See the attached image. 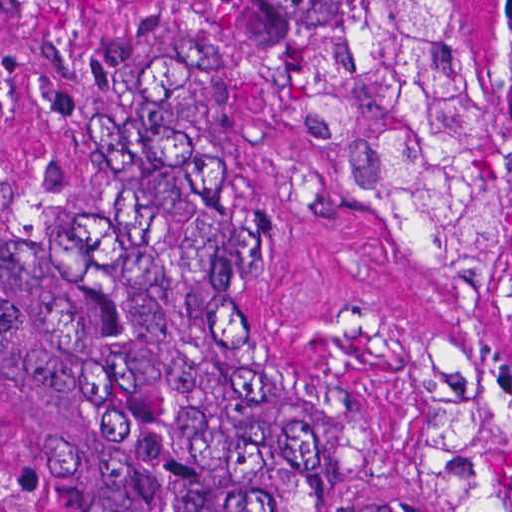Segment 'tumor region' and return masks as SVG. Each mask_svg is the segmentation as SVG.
Segmentation results:
<instances>
[{"mask_svg":"<svg viewBox=\"0 0 512 512\" xmlns=\"http://www.w3.org/2000/svg\"><path fill=\"white\" fill-rule=\"evenodd\" d=\"M338 131L333 179L406 273L483 288L512 238V0L496 111L453 0H212ZM443 512H512V364L439 340ZM0 448L61 512H372L265 312L227 180L173 74L134 80L96 188L0 133Z\"/></svg>","mask_w":512,"mask_h":512,"instance_id":"e687c5a6","label":"tumor region"}]
</instances>
